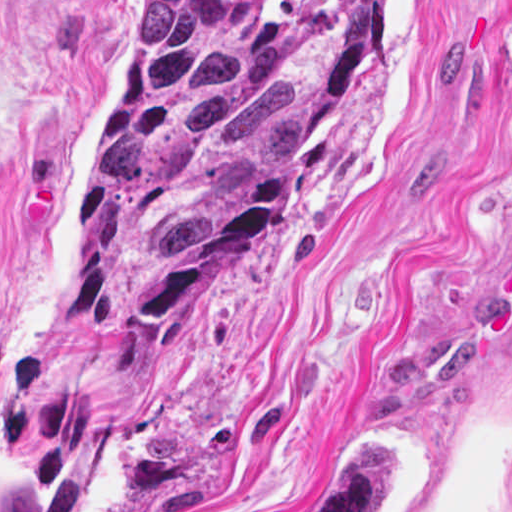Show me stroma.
<instances>
[{"label":"stroma","instance_id":"obj_1","mask_svg":"<svg viewBox=\"0 0 512 512\" xmlns=\"http://www.w3.org/2000/svg\"><path fill=\"white\" fill-rule=\"evenodd\" d=\"M150 0H0V512H512V0H387L317 165L169 351L79 308L92 119Z\"/></svg>","mask_w":512,"mask_h":512}]
</instances>
